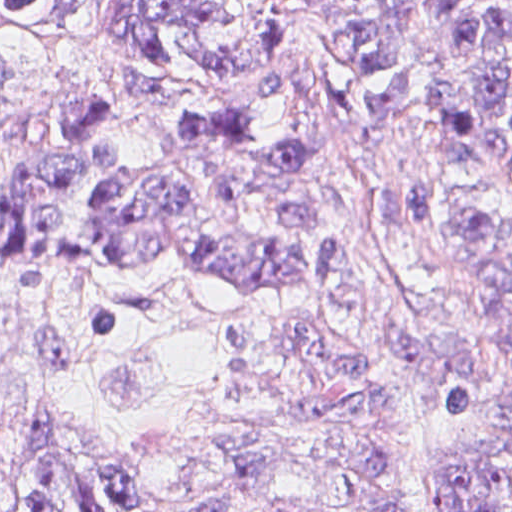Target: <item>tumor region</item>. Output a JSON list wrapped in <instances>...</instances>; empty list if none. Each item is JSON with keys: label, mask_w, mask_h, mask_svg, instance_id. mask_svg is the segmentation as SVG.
I'll return each mask as SVG.
<instances>
[{"label": "tumor region", "mask_w": 512, "mask_h": 512, "mask_svg": "<svg viewBox=\"0 0 512 512\" xmlns=\"http://www.w3.org/2000/svg\"><path fill=\"white\" fill-rule=\"evenodd\" d=\"M422 1L448 31L454 69L440 93L439 131L512 181V0ZM288 2L343 71L347 97L336 119L373 219L417 235L432 192L397 170L384 149L390 120L410 93L401 0H372L339 17H324L317 0ZM0 27L101 43L173 107H193L214 83L268 56V18L258 0H0ZM257 90L287 123L285 137L264 132L255 106H198L169 129L154 160L124 153L113 128L120 104L56 100L45 156L0 190V239L23 258L61 240L69 234L66 199L81 188L111 266L165 258L219 276L250 298L322 281L340 265L342 224L338 197L321 185L315 128L288 73L266 74ZM474 252L505 323L512 367V236L480 220ZM258 318L281 369L280 401L268 416L335 441L333 472L350 478L363 512H411L378 436L389 408L377 375L415 356L419 332L395 323L380 349L369 351L318 326ZM428 371L447 396L443 512H512V456L447 434L472 388L461 345L439 334ZM482 419L512 434V386L503 407ZM222 442L247 478L297 467L269 445ZM162 473L56 454L31 462L25 477H0V512H152ZM198 503L186 512L235 509Z\"/></svg>", "instance_id": "e687c5a6"}]
</instances>
